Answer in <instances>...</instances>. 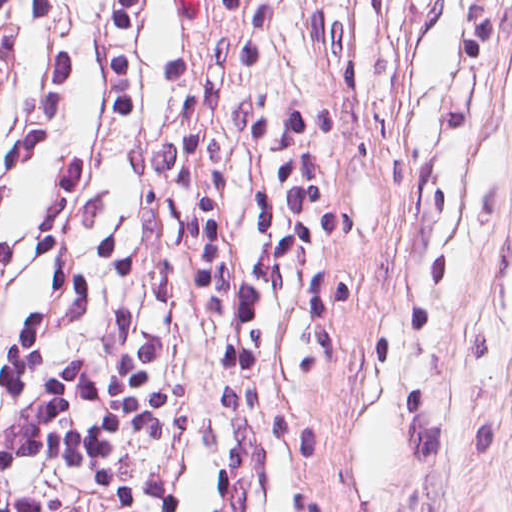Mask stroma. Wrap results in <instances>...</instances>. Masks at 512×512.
Returning <instances> with one entry per match:
<instances>
[{
  "mask_svg": "<svg viewBox=\"0 0 512 512\" xmlns=\"http://www.w3.org/2000/svg\"><path fill=\"white\" fill-rule=\"evenodd\" d=\"M311 512H512V0H212Z\"/></svg>",
  "mask_w": 512,
  "mask_h": 512,
  "instance_id": "1",
  "label": "stroma"
}]
</instances>
